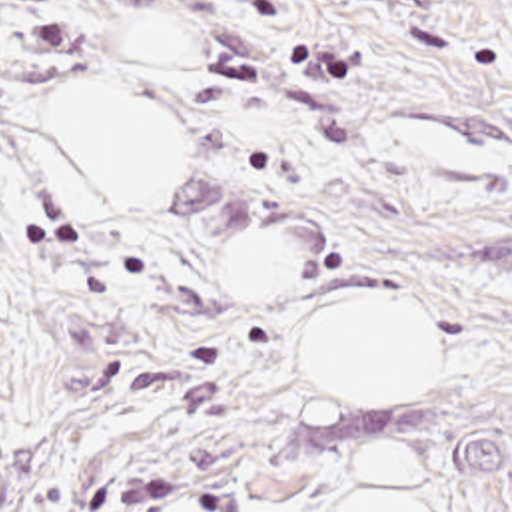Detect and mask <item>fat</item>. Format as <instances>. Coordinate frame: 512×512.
<instances>
[{
  "label": "fat",
  "mask_w": 512,
  "mask_h": 512,
  "mask_svg": "<svg viewBox=\"0 0 512 512\" xmlns=\"http://www.w3.org/2000/svg\"><path fill=\"white\" fill-rule=\"evenodd\" d=\"M47 143L71 171L85 207H151L187 173V119L139 103L113 85L71 81L41 117ZM225 293H261L295 279V245L267 229L225 241L215 253ZM442 353L430 313L392 297L336 299L297 329L295 361L304 388L332 404H412L428 390ZM422 458L398 446L362 450L338 512H436ZM167 512H223L189 496Z\"/></svg>",
  "instance_id": "53f6f03d"
}]
</instances>
